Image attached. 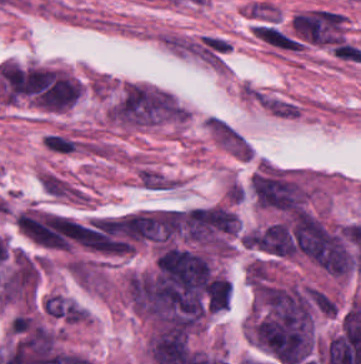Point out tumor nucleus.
I'll use <instances>...</instances> for the list:
<instances>
[{"label": "tumor nucleus", "mask_w": 361, "mask_h": 364, "mask_svg": "<svg viewBox=\"0 0 361 364\" xmlns=\"http://www.w3.org/2000/svg\"><path fill=\"white\" fill-rule=\"evenodd\" d=\"M232 284L226 277H212L206 286L207 310H227Z\"/></svg>", "instance_id": "obj_4"}, {"label": "tumor nucleus", "mask_w": 361, "mask_h": 364, "mask_svg": "<svg viewBox=\"0 0 361 364\" xmlns=\"http://www.w3.org/2000/svg\"><path fill=\"white\" fill-rule=\"evenodd\" d=\"M251 192L260 206L274 210L296 212L305 206V195L298 184L276 172L253 175Z\"/></svg>", "instance_id": "obj_2"}, {"label": "tumor nucleus", "mask_w": 361, "mask_h": 364, "mask_svg": "<svg viewBox=\"0 0 361 364\" xmlns=\"http://www.w3.org/2000/svg\"><path fill=\"white\" fill-rule=\"evenodd\" d=\"M297 243L324 270L341 275L352 267L342 237L312 217L298 218Z\"/></svg>", "instance_id": "obj_1"}, {"label": "tumor nucleus", "mask_w": 361, "mask_h": 364, "mask_svg": "<svg viewBox=\"0 0 361 364\" xmlns=\"http://www.w3.org/2000/svg\"><path fill=\"white\" fill-rule=\"evenodd\" d=\"M44 312L66 322H77L83 317L85 309L67 297L49 295L46 298Z\"/></svg>", "instance_id": "obj_3"}]
</instances>
